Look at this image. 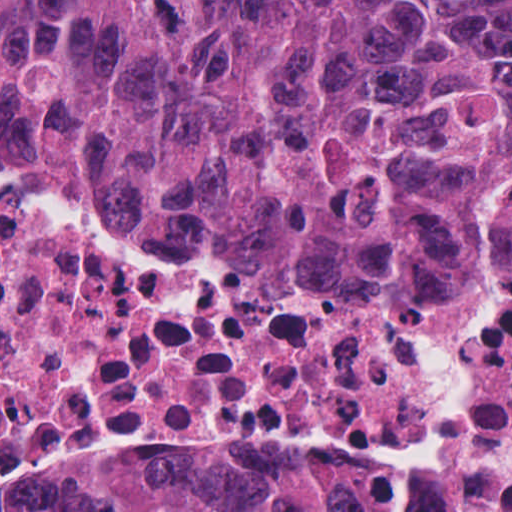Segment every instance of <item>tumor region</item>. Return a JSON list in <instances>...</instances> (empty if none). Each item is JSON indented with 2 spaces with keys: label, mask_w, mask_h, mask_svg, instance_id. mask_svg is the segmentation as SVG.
I'll list each match as a JSON object with an SVG mask.
<instances>
[{
  "label": "tumor region",
  "mask_w": 512,
  "mask_h": 512,
  "mask_svg": "<svg viewBox=\"0 0 512 512\" xmlns=\"http://www.w3.org/2000/svg\"><path fill=\"white\" fill-rule=\"evenodd\" d=\"M0 159L148 234L489 263L512 0H0ZM41 512H356V452L188 456Z\"/></svg>",
  "instance_id": "obj_1"
}]
</instances>
